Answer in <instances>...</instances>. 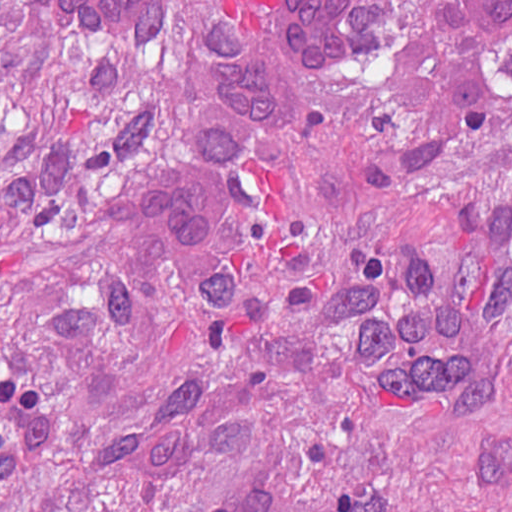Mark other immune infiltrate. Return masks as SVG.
Listing matches in <instances>:
<instances>
[{
	"mask_svg": "<svg viewBox=\"0 0 512 512\" xmlns=\"http://www.w3.org/2000/svg\"><path fill=\"white\" fill-rule=\"evenodd\" d=\"M59 31L82 44H128L152 31L164 0H33ZM202 162V161H201ZM144 164L129 177L126 218L152 250L196 254L211 240L215 170Z\"/></svg>",
	"mask_w": 512,
	"mask_h": 512,
	"instance_id": "other-immune-infiltrate-1",
	"label": "other immune infiltrate"
}]
</instances>
